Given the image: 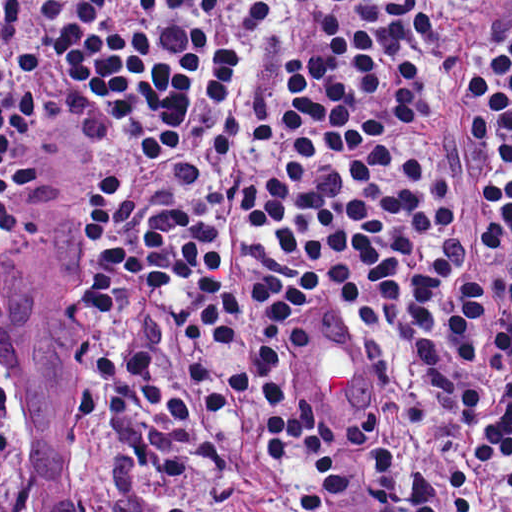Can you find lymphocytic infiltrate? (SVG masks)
<instances>
[{"instance_id":"lymphocytic-infiltrate-1","label":"lymphocytic infiltrate","mask_w":512,"mask_h":512,"mask_svg":"<svg viewBox=\"0 0 512 512\" xmlns=\"http://www.w3.org/2000/svg\"><path fill=\"white\" fill-rule=\"evenodd\" d=\"M85 154L70 404L269 512L512 493V0H0V222ZM385 368L356 422L305 362Z\"/></svg>"}]
</instances>
